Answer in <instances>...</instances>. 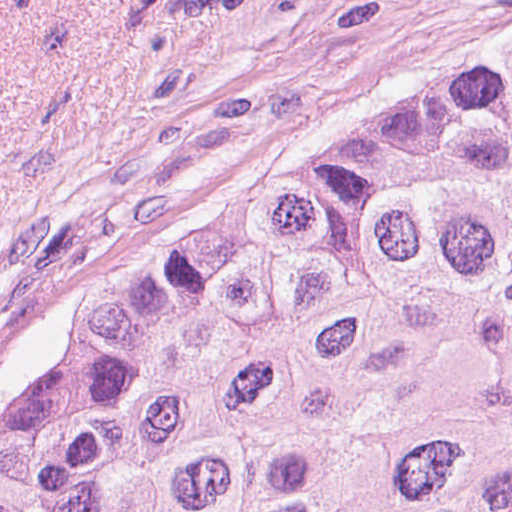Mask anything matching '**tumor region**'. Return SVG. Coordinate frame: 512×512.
<instances>
[{"instance_id":"e687c5a6","label":"tumor region","mask_w":512,"mask_h":512,"mask_svg":"<svg viewBox=\"0 0 512 512\" xmlns=\"http://www.w3.org/2000/svg\"><path fill=\"white\" fill-rule=\"evenodd\" d=\"M1 512H512V51L128 270Z\"/></svg>"}]
</instances>
